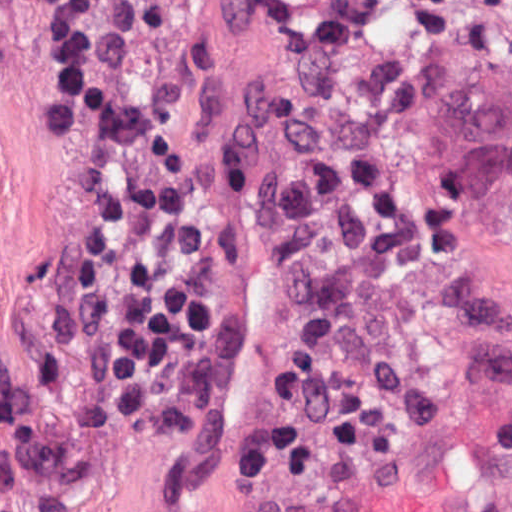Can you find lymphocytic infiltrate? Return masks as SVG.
<instances>
[{
  "instance_id": "obj_1",
  "label": "lymphocytic infiltrate",
  "mask_w": 512,
  "mask_h": 512,
  "mask_svg": "<svg viewBox=\"0 0 512 512\" xmlns=\"http://www.w3.org/2000/svg\"><path fill=\"white\" fill-rule=\"evenodd\" d=\"M96 4L59 0L48 25L46 43L64 79V124L83 94ZM79 155L91 192L79 283L106 370L103 401L108 412L157 422L188 444L216 419L237 379V267L128 115L94 120Z\"/></svg>"
}]
</instances>
